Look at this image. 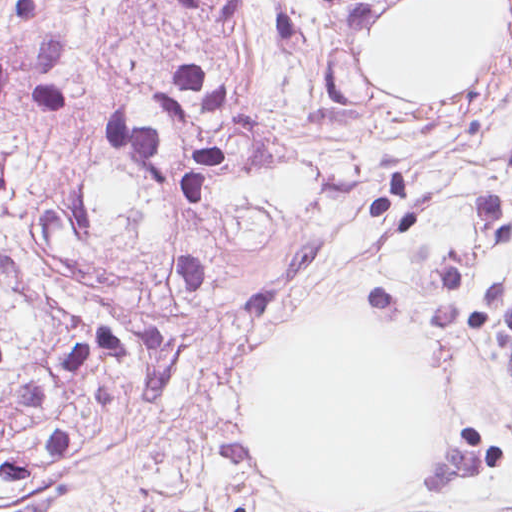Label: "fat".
Instances as JSON below:
<instances>
[{"label": "fat", "instance_id": "obj_1", "mask_svg": "<svg viewBox=\"0 0 512 512\" xmlns=\"http://www.w3.org/2000/svg\"><path fill=\"white\" fill-rule=\"evenodd\" d=\"M449 394L392 322L318 320L280 339L245 402V446L277 480L346 509H388L438 460Z\"/></svg>", "mask_w": 512, "mask_h": 512}]
</instances>
